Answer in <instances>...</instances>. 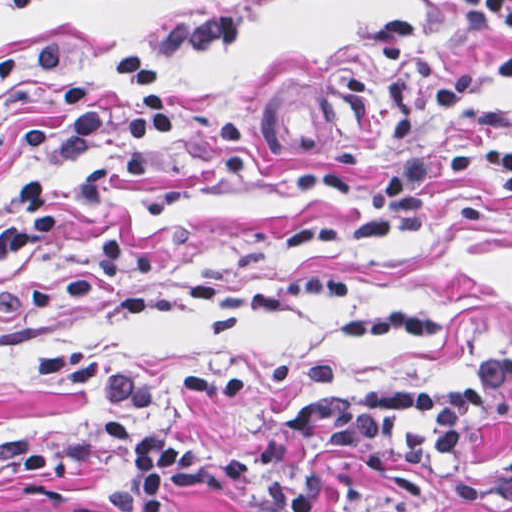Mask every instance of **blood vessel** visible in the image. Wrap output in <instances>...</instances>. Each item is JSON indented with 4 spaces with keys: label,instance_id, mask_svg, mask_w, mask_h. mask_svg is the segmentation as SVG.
<instances>
[{
    "label": "blood vessel",
    "instance_id": "blood-vessel-1",
    "mask_svg": "<svg viewBox=\"0 0 512 512\" xmlns=\"http://www.w3.org/2000/svg\"><path fill=\"white\" fill-rule=\"evenodd\" d=\"M325 82L278 78L253 92V123L269 154L302 169L324 171L356 137L362 106L315 88Z\"/></svg>",
    "mask_w": 512,
    "mask_h": 512
}]
</instances>
